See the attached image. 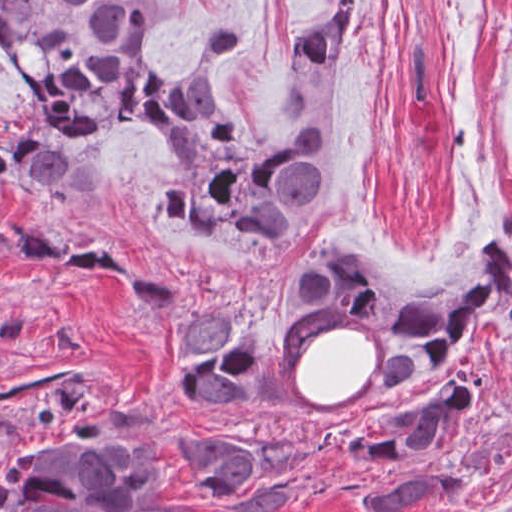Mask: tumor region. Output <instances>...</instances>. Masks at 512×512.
<instances>
[{
	"label": "tumor region",
	"instance_id": "tumor-region-1",
	"mask_svg": "<svg viewBox=\"0 0 512 512\" xmlns=\"http://www.w3.org/2000/svg\"><path fill=\"white\" fill-rule=\"evenodd\" d=\"M164 0H0V60L29 100L0 118V197L23 192L70 212L108 200L107 137L140 128L166 140L148 221L213 238L240 267L268 268L324 199L344 134L255 139L219 98L243 35L239 14L218 24L179 74L154 61V18ZM360 0H337L304 34L296 64L328 69L360 48ZM76 268L128 285L164 333V392L179 403L267 410L277 400L266 346L226 300L189 311L179 284L155 279L103 240L59 243L31 221L0 226V264ZM276 305L294 332L314 318L356 317L384 328L381 393L439 377L489 306L512 311V247L481 234L443 281L415 292L389 287L356 253L307 248L277 282ZM486 402L471 372L449 373L352 415L325 422L308 443L371 471L357 485L361 512H416L450 494L451 455ZM23 403L32 428L0 449V512H198L159 497L166 462L150 459L142 427L96 411L74 371L0 389ZM215 512H286L302 501L323 459L247 436L199 431L180 450ZM388 470V472H375Z\"/></svg>",
	"mask_w": 512,
	"mask_h": 512
}]
</instances>
